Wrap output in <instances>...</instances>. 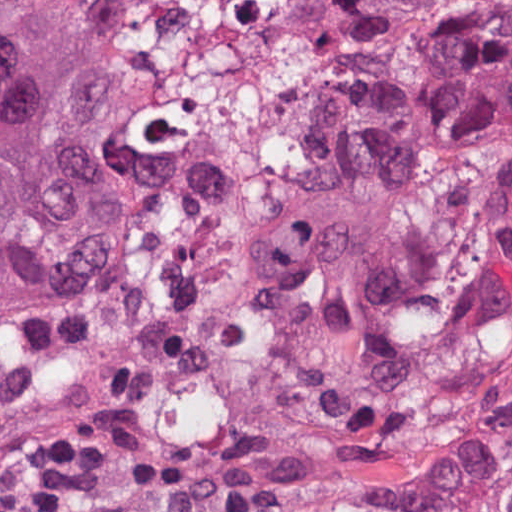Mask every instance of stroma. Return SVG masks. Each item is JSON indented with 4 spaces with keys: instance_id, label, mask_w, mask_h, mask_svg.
Listing matches in <instances>:
<instances>
[{
    "instance_id": "stroma-1",
    "label": "stroma",
    "mask_w": 512,
    "mask_h": 512,
    "mask_svg": "<svg viewBox=\"0 0 512 512\" xmlns=\"http://www.w3.org/2000/svg\"><path fill=\"white\" fill-rule=\"evenodd\" d=\"M57 0H0V29ZM143 82L110 171L126 252L77 290L0 300V512L58 436L124 426L57 512H227L236 375L296 254L277 202L354 0H88Z\"/></svg>"
}]
</instances>
